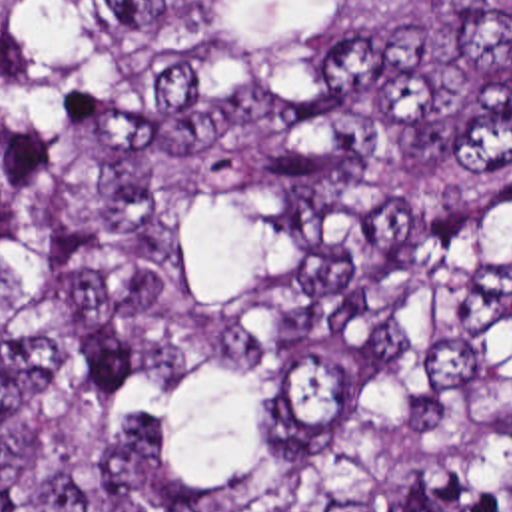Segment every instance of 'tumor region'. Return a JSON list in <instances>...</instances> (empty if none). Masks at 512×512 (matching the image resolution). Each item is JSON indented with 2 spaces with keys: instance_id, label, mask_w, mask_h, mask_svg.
Masks as SVG:
<instances>
[{
  "instance_id": "tumor-region-1",
  "label": "tumor region",
  "mask_w": 512,
  "mask_h": 512,
  "mask_svg": "<svg viewBox=\"0 0 512 512\" xmlns=\"http://www.w3.org/2000/svg\"><path fill=\"white\" fill-rule=\"evenodd\" d=\"M0 512H512V0H0Z\"/></svg>"
}]
</instances>
